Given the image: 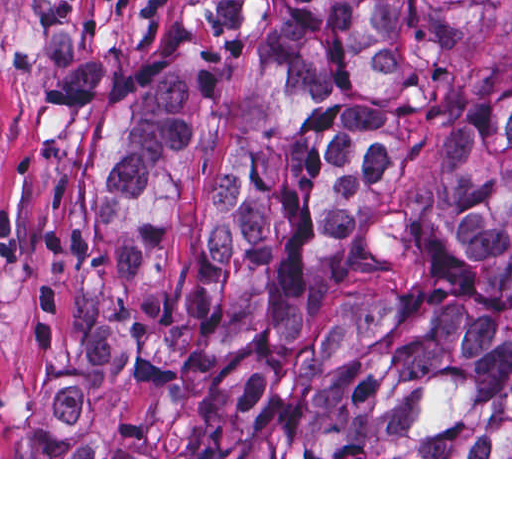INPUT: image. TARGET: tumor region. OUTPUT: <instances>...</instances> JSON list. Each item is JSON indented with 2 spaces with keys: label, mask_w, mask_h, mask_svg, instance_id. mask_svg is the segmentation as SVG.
<instances>
[{
  "label": "tumor region",
  "mask_w": 512,
  "mask_h": 512,
  "mask_svg": "<svg viewBox=\"0 0 512 512\" xmlns=\"http://www.w3.org/2000/svg\"><path fill=\"white\" fill-rule=\"evenodd\" d=\"M183 378L186 457H512V0H193L113 99L21 457Z\"/></svg>",
  "instance_id": "obj_1"
}]
</instances>
